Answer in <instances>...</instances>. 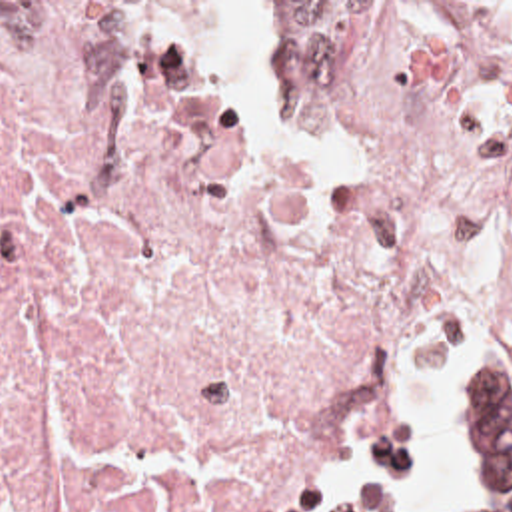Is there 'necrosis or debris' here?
<instances>
[{
    "label": "necrosis or debris",
    "instance_id": "1",
    "mask_svg": "<svg viewBox=\"0 0 512 512\" xmlns=\"http://www.w3.org/2000/svg\"><path fill=\"white\" fill-rule=\"evenodd\" d=\"M512 319V2H0V512H315L423 303Z\"/></svg>",
    "mask_w": 512,
    "mask_h": 512
}]
</instances>
